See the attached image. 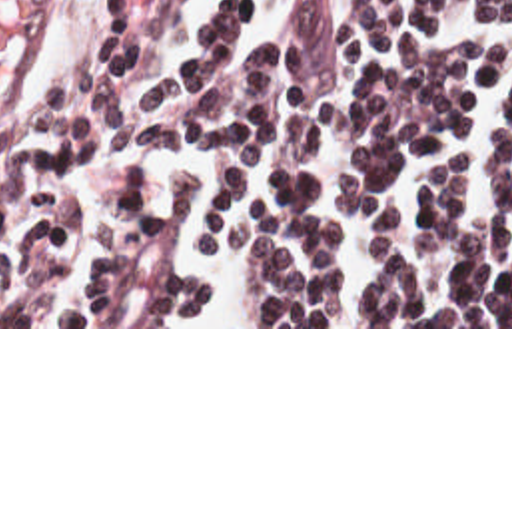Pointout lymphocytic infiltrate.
<instances>
[{"label": "lymphocytic infiltrate", "mask_w": 512, "mask_h": 512, "mask_svg": "<svg viewBox=\"0 0 512 512\" xmlns=\"http://www.w3.org/2000/svg\"><path fill=\"white\" fill-rule=\"evenodd\" d=\"M185 2L71 0L41 77L1 121L0 327H181L207 299L211 285L167 261L189 175L169 173L153 205L121 167L95 225L83 221L71 167L103 143L225 163L195 251H245L261 327H512V243L468 213L472 159L422 195L424 245L452 263L450 287L422 281L394 245H378V287H356L337 231L309 207L315 143H329L343 207L382 231L404 223L410 171L470 129L500 57L494 44L430 38L462 6L512 28V0H273L271 32L237 55L253 0H223L193 48L137 85L143 53ZM490 167L512 213V91Z\"/></svg>", "instance_id": "f902f5d3"}]
</instances>
